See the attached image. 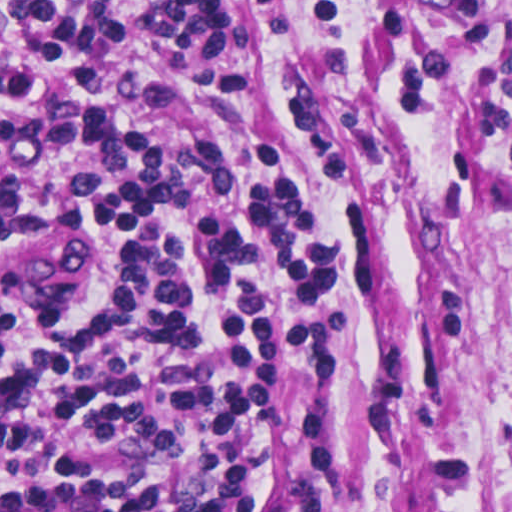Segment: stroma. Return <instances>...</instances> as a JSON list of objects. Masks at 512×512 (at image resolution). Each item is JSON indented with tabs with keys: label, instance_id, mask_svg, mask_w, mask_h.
<instances>
[{
	"label": "stroma",
	"instance_id": "35a3bbf8",
	"mask_svg": "<svg viewBox=\"0 0 512 512\" xmlns=\"http://www.w3.org/2000/svg\"><path fill=\"white\" fill-rule=\"evenodd\" d=\"M114 0L118 75L169 96L156 145L207 137L251 159L273 126L298 143L317 205L361 265V340L344 347L289 512H512V0H272L231 9L217 58ZM259 50L256 95L225 69ZM51 207H0L54 221ZM98 232L20 309L106 293Z\"/></svg>",
	"mask_w": 512,
	"mask_h": 512
}]
</instances>
